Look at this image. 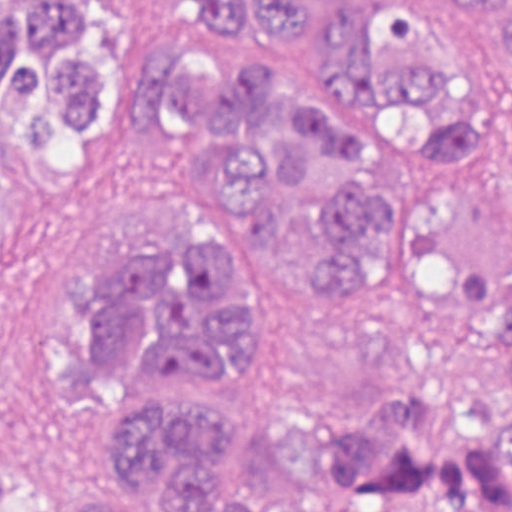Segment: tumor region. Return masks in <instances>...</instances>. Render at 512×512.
Returning <instances> with one entry per match:
<instances>
[{
	"instance_id": "1",
	"label": "tumor region",
	"mask_w": 512,
	"mask_h": 512,
	"mask_svg": "<svg viewBox=\"0 0 512 512\" xmlns=\"http://www.w3.org/2000/svg\"><path fill=\"white\" fill-rule=\"evenodd\" d=\"M202 21L199 72L158 54L139 79ZM489 84H512V0H0V266L135 119L183 163L166 243L72 271L85 461L1 471L0 512H512Z\"/></svg>"
}]
</instances>
